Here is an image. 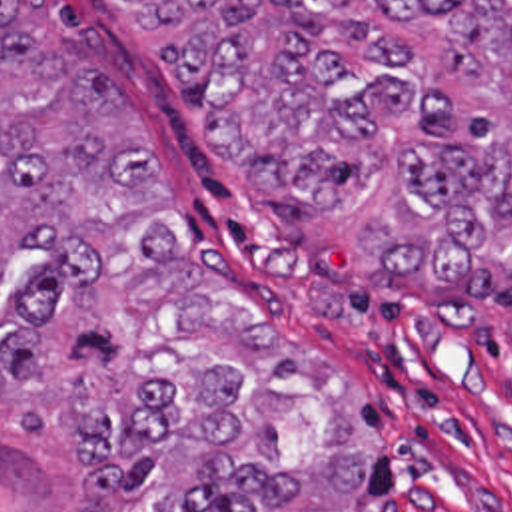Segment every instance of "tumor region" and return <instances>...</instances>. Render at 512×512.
Wrapping results in <instances>:
<instances>
[{
  "instance_id": "tumor-region-1",
  "label": "tumor region",
  "mask_w": 512,
  "mask_h": 512,
  "mask_svg": "<svg viewBox=\"0 0 512 512\" xmlns=\"http://www.w3.org/2000/svg\"><path fill=\"white\" fill-rule=\"evenodd\" d=\"M228 179L378 281L512 249V0H118ZM168 179L48 0H0V323L46 462L94 512H348L370 450L334 364L170 251Z\"/></svg>"
}]
</instances>
